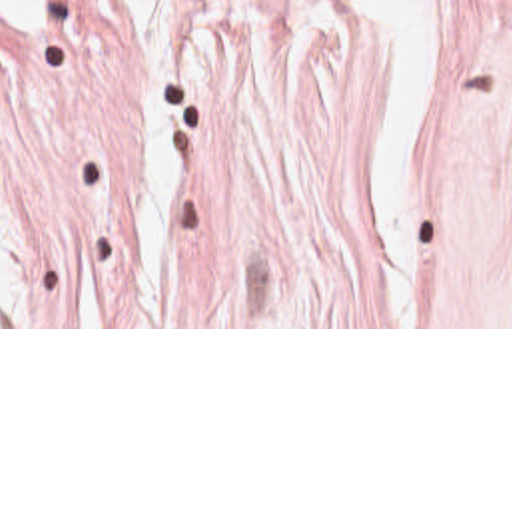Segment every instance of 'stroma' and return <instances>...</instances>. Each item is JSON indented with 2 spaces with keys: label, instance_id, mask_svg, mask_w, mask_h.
I'll return each mask as SVG.
<instances>
[{
  "label": "stroma",
  "instance_id": "obj_1",
  "mask_svg": "<svg viewBox=\"0 0 512 512\" xmlns=\"http://www.w3.org/2000/svg\"><path fill=\"white\" fill-rule=\"evenodd\" d=\"M0 329H512V0L0 16Z\"/></svg>",
  "mask_w": 512,
  "mask_h": 512
}]
</instances>
